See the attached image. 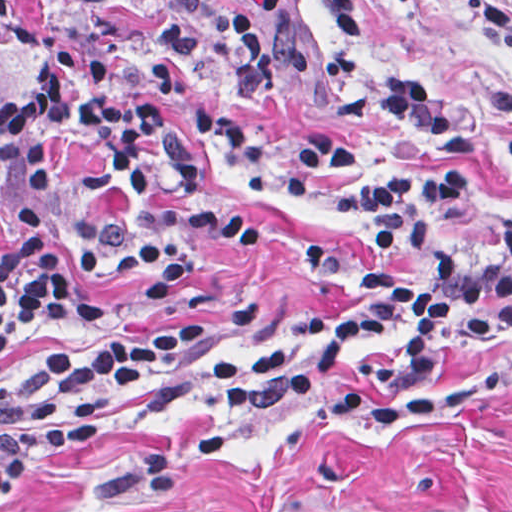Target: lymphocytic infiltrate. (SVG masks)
<instances>
[{"instance_id": "lymphocytic-infiltrate-1", "label": "lymphocytic infiltrate", "mask_w": 512, "mask_h": 512, "mask_svg": "<svg viewBox=\"0 0 512 512\" xmlns=\"http://www.w3.org/2000/svg\"><path fill=\"white\" fill-rule=\"evenodd\" d=\"M13 0H0L5 10ZM353 39L359 0H317ZM512 56L502 0H462ZM83 37L45 47L38 78L0 104V356L16 341L87 325L106 307L79 287L84 260L160 300L200 278L276 215L289 185L340 171L334 133L270 157L253 94L304 109L370 107L440 148L459 129L411 67L393 60L327 83L320 37L297 0H79ZM512 149V146H508ZM337 211L369 257L331 251L358 311L303 318L247 357L232 383L206 357L218 328H183L51 352L0 393V504L77 457L126 401H346L375 395L512 337V199L457 167H367L339 179Z\"/></svg>"}]
</instances>
